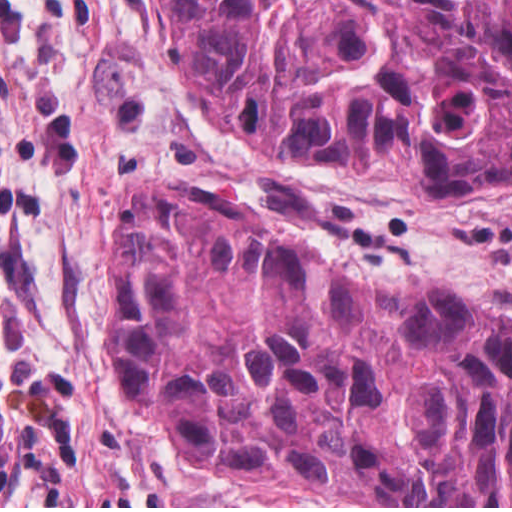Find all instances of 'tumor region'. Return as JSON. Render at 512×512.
Masks as SVG:
<instances>
[{
	"mask_svg": "<svg viewBox=\"0 0 512 512\" xmlns=\"http://www.w3.org/2000/svg\"><path fill=\"white\" fill-rule=\"evenodd\" d=\"M226 140L305 166L512 193V0H150ZM401 283L400 285H398ZM106 389L199 475H236L509 315L437 282L358 283L182 181L106 232Z\"/></svg>",
	"mask_w": 512,
	"mask_h": 512,
	"instance_id": "tumor-region-1",
	"label": "tumor region"
}]
</instances>
